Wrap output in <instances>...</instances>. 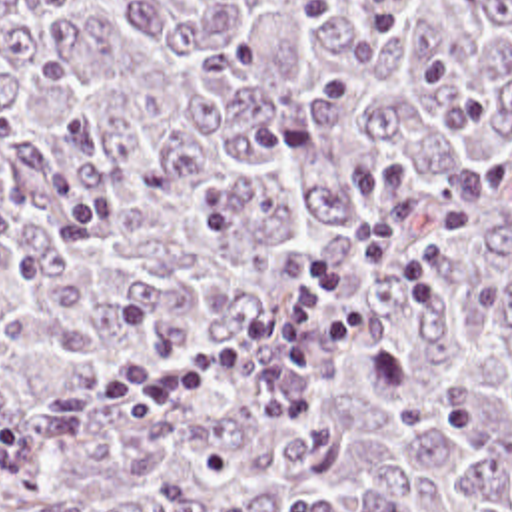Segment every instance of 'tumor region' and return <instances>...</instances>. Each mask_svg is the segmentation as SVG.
Listing matches in <instances>:
<instances>
[{"label": "tumor region", "instance_id": "obj_1", "mask_svg": "<svg viewBox=\"0 0 512 512\" xmlns=\"http://www.w3.org/2000/svg\"><path fill=\"white\" fill-rule=\"evenodd\" d=\"M312 0H0V512H512V0H406L400 36ZM472 202L422 318L390 270L318 334L306 414L248 362L115 422L141 302L229 334L306 260Z\"/></svg>", "mask_w": 512, "mask_h": 512}]
</instances>
